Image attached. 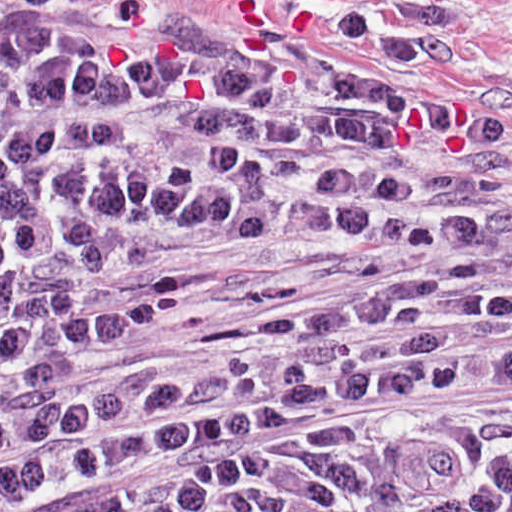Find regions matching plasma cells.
<instances>
[{"label":"plasma cells","mask_w":512,"mask_h":512,"mask_svg":"<svg viewBox=\"0 0 512 512\" xmlns=\"http://www.w3.org/2000/svg\"><path fill=\"white\" fill-rule=\"evenodd\" d=\"M197 224L409 239L414 270L81 387L83 352L207 284L83 269ZM0 512H512V222L466 198L447 112L0 9Z\"/></svg>","instance_id":"1"}]
</instances>
